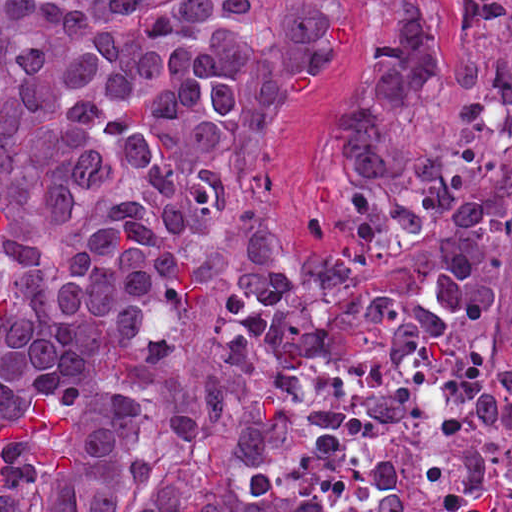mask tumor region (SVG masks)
<instances>
[{
  "label": "tumor region",
  "instance_id": "obj_1",
  "mask_svg": "<svg viewBox=\"0 0 512 512\" xmlns=\"http://www.w3.org/2000/svg\"><path fill=\"white\" fill-rule=\"evenodd\" d=\"M492 60L455 57L464 134L512 146V0H450ZM348 17H371L360 89L328 141L348 239L240 238L220 360L188 358L166 302L210 285L307 78ZM444 43V0H0V197L78 242L0 217V512H335L292 504L277 425L300 343L456 357L490 374L453 443L368 512H512L511 226L484 161L426 151L406 102Z\"/></svg>",
  "mask_w": 512,
  "mask_h": 512
}]
</instances>
